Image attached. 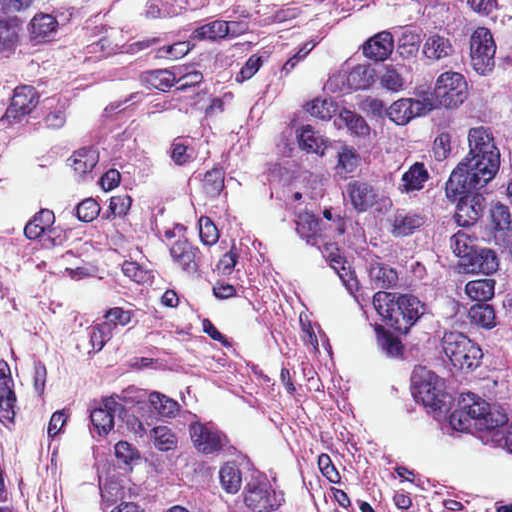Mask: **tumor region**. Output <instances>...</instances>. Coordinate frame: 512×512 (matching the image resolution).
Returning <instances> with one entry per match:
<instances>
[{"mask_svg":"<svg viewBox=\"0 0 512 512\" xmlns=\"http://www.w3.org/2000/svg\"><path fill=\"white\" fill-rule=\"evenodd\" d=\"M101 0H0V46ZM420 20L334 92L287 160L343 284L448 428L512 450V0ZM111 512H271L249 466L143 389L103 409ZM0 512H19L4 460Z\"/></svg>","mask_w":512,"mask_h":512,"instance_id":"e687c5a6","label":"tumor region"}]
</instances>
